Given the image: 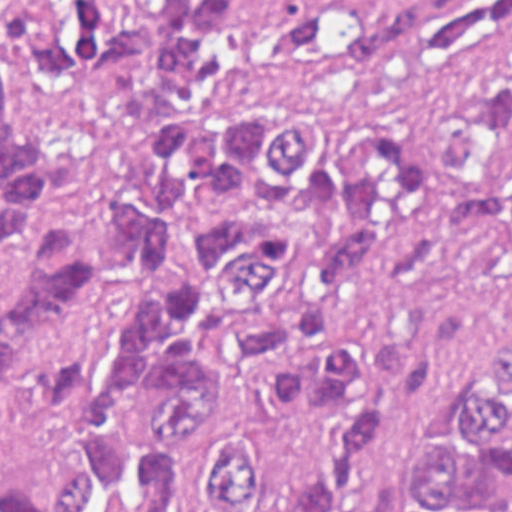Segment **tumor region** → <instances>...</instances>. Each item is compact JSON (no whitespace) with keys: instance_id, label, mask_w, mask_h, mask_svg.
Here are the masks:
<instances>
[{"instance_id":"tumor-region-1","label":"tumor region","mask_w":512,"mask_h":512,"mask_svg":"<svg viewBox=\"0 0 512 512\" xmlns=\"http://www.w3.org/2000/svg\"><path fill=\"white\" fill-rule=\"evenodd\" d=\"M512 0H0V512H343L467 318L367 284L413 150L240 65H425ZM446 237L512 265V37L442 168ZM390 512H512V337Z\"/></svg>"}]
</instances>
